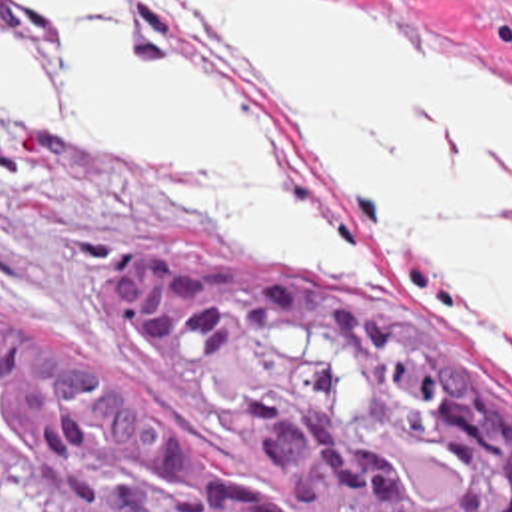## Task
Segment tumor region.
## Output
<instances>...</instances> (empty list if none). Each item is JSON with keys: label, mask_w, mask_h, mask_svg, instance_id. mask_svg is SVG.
I'll return each instance as SVG.
<instances>
[{"label": "tumor region", "mask_w": 512, "mask_h": 512, "mask_svg": "<svg viewBox=\"0 0 512 512\" xmlns=\"http://www.w3.org/2000/svg\"><path fill=\"white\" fill-rule=\"evenodd\" d=\"M135 339L285 462L305 512H512V394L419 317L301 261L149 249ZM0 512H275L91 347L0 305Z\"/></svg>", "instance_id": "e687c5a6"}]
</instances>
